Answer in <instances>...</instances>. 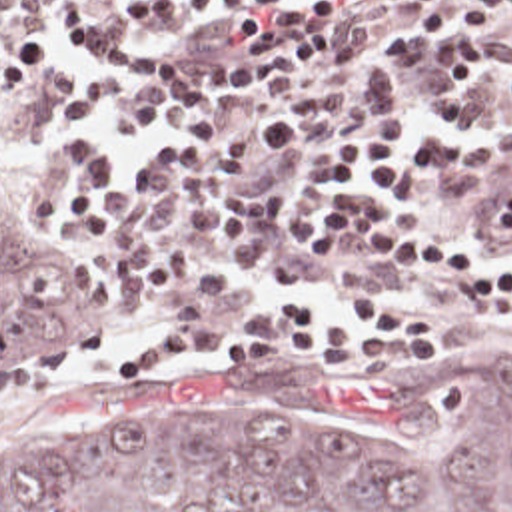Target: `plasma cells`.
Returning <instances> with one entry per match:
<instances>
[{
    "instance_id": "plasma-cells-1",
    "label": "plasma cells",
    "mask_w": 512,
    "mask_h": 512,
    "mask_svg": "<svg viewBox=\"0 0 512 512\" xmlns=\"http://www.w3.org/2000/svg\"><path fill=\"white\" fill-rule=\"evenodd\" d=\"M58 0H0L22 29H40ZM66 0H60V3ZM176 97V67L142 61L114 73H86L82 95L64 101V125L86 131L98 111L108 139H144ZM36 180V226L74 242H100V262L120 280V316L140 322L166 284L190 290L176 322L222 320L256 290L258 278L232 262L288 280H314L330 260L328 238L302 218L262 204L180 188L134 174L110 180V156L80 137H48ZM425 174L453 198L475 204L485 242L512 244V139L439 144Z\"/></svg>"
}]
</instances>
